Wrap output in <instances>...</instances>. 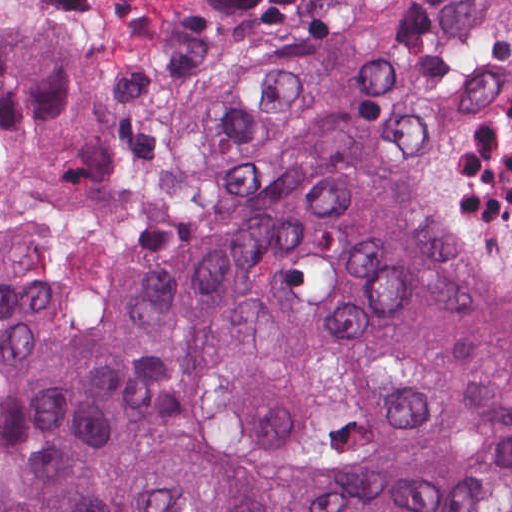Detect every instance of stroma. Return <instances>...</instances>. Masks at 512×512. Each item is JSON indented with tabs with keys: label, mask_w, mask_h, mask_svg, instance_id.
I'll use <instances>...</instances> for the list:
<instances>
[{
	"label": "stroma",
	"mask_w": 512,
	"mask_h": 512,
	"mask_svg": "<svg viewBox=\"0 0 512 512\" xmlns=\"http://www.w3.org/2000/svg\"><path fill=\"white\" fill-rule=\"evenodd\" d=\"M84 137L48 178L0 159V249L32 246L74 326L144 317L160 265L269 155L354 146L462 259L512 274V0H0Z\"/></svg>",
	"instance_id": "35a3bbf8"
}]
</instances>
